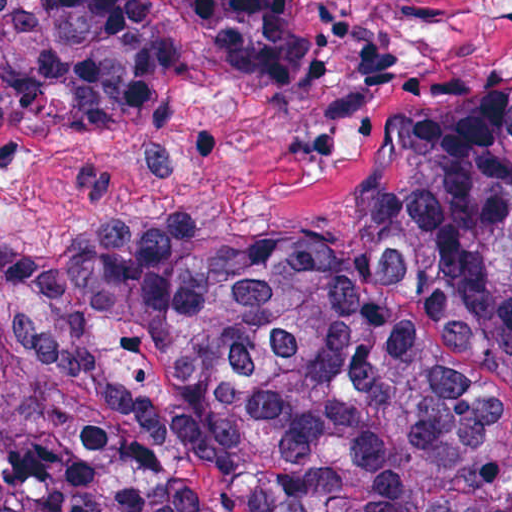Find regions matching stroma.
Returning <instances> with one entry per match:
<instances>
[{"label":"stroma","mask_w":512,"mask_h":512,"mask_svg":"<svg viewBox=\"0 0 512 512\" xmlns=\"http://www.w3.org/2000/svg\"><path fill=\"white\" fill-rule=\"evenodd\" d=\"M177 52L130 118L10 126L66 147L82 193L46 230H329L364 188L390 117L473 77H512V0H293L312 69L230 70L196 21L146 0Z\"/></svg>","instance_id":"stroma-1"}]
</instances>
